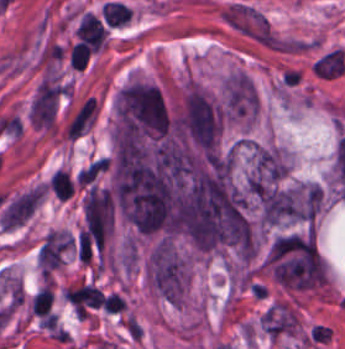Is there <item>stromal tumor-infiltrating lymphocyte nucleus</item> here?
<instances>
[{
	"label": "stromal tumor-infiltrating lymphocyte nucleus",
	"mask_w": 345,
	"mask_h": 349,
	"mask_svg": "<svg viewBox=\"0 0 345 349\" xmlns=\"http://www.w3.org/2000/svg\"><path fill=\"white\" fill-rule=\"evenodd\" d=\"M51 191L61 199H68L73 194L72 180L67 171L55 170L51 177Z\"/></svg>",
	"instance_id": "bc302bb0"
},
{
	"label": "stromal tumor-infiltrating lymphocyte nucleus",
	"mask_w": 345,
	"mask_h": 349,
	"mask_svg": "<svg viewBox=\"0 0 345 349\" xmlns=\"http://www.w3.org/2000/svg\"><path fill=\"white\" fill-rule=\"evenodd\" d=\"M53 298L48 284L32 295L30 301L31 314L48 316Z\"/></svg>",
	"instance_id": "52c7bb5b"
},
{
	"label": "stromal tumor-infiltrating lymphocyte nucleus",
	"mask_w": 345,
	"mask_h": 349,
	"mask_svg": "<svg viewBox=\"0 0 345 349\" xmlns=\"http://www.w3.org/2000/svg\"><path fill=\"white\" fill-rule=\"evenodd\" d=\"M89 57V47L84 43L77 42L70 50V63L71 65L84 69L87 66Z\"/></svg>",
	"instance_id": "3290ff9b"
}]
</instances>
